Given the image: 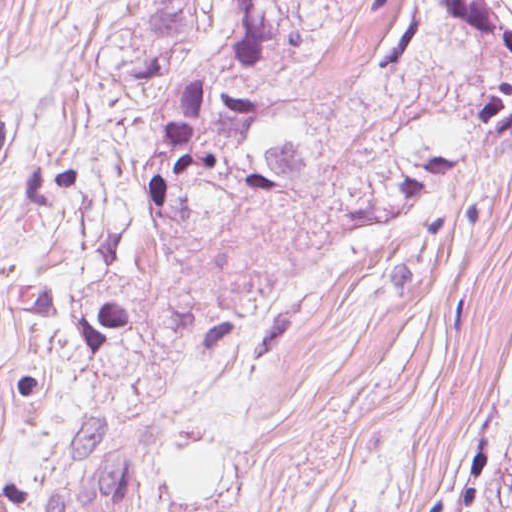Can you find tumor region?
I'll return each mask as SVG.
<instances>
[{
	"label": "tumor region",
	"mask_w": 512,
	"mask_h": 512,
	"mask_svg": "<svg viewBox=\"0 0 512 512\" xmlns=\"http://www.w3.org/2000/svg\"><path fill=\"white\" fill-rule=\"evenodd\" d=\"M392 0H156L136 45L140 260L96 286L81 332L156 312L146 280L201 225L249 205H311L322 141L298 109L303 68ZM406 104L341 182L333 240L483 160L512 158V0H410L370 93ZM332 240V241H333ZM499 512H512V408Z\"/></svg>",
	"instance_id": "1"
}]
</instances>
